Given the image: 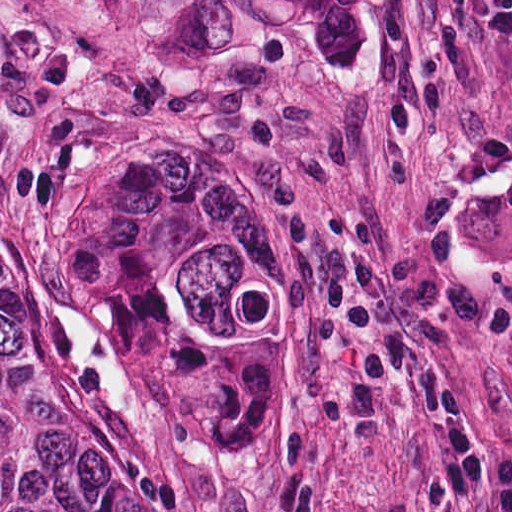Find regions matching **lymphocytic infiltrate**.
Segmentation results:
<instances>
[{
	"label": "lymphocytic infiltrate",
	"mask_w": 512,
	"mask_h": 512,
	"mask_svg": "<svg viewBox=\"0 0 512 512\" xmlns=\"http://www.w3.org/2000/svg\"><path fill=\"white\" fill-rule=\"evenodd\" d=\"M281 240L279 293L315 328L344 341L370 394L395 382L424 414L445 425L468 482L480 480L461 405L441 364L409 343L359 291L342 258L331 207L298 175L274 168L265 187Z\"/></svg>",
	"instance_id": "1"
}]
</instances>
